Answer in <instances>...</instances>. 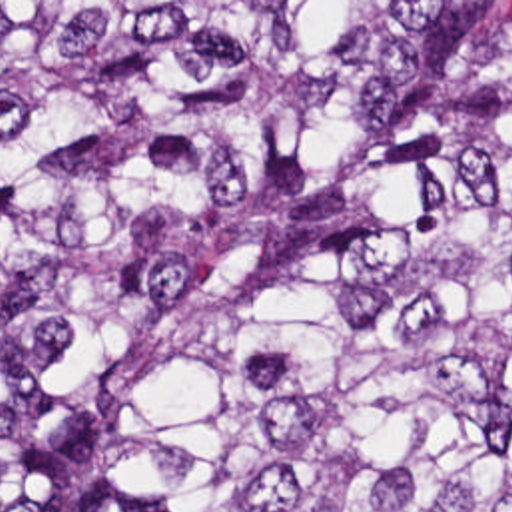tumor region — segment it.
<instances>
[{
  "label": "tumor region",
  "mask_w": 512,
  "mask_h": 512,
  "mask_svg": "<svg viewBox=\"0 0 512 512\" xmlns=\"http://www.w3.org/2000/svg\"><path fill=\"white\" fill-rule=\"evenodd\" d=\"M15 512H512V2H0Z\"/></svg>",
  "instance_id": "obj_1"
}]
</instances>
